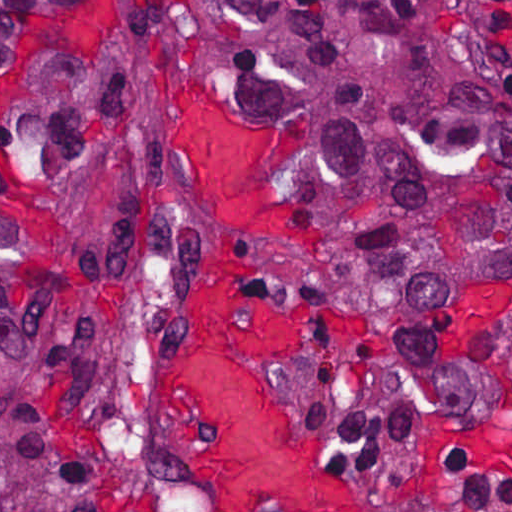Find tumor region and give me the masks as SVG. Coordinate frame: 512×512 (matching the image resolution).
I'll list each match as a JSON object with an SVG mask.
<instances>
[{
  "instance_id": "obj_1",
  "label": "tumor region",
  "mask_w": 512,
  "mask_h": 512,
  "mask_svg": "<svg viewBox=\"0 0 512 512\" xmlns=\"http://www.w3.org/2000/svg\"><path fill=\"white\" fill-rule=\"evenodd\" d=\"M314 123L347 256L275 286L383 307L355 460L471 415L454 304L512 291V44L490 0H0V512H115L52 357L178 206L151 156L181 78Z\"/></svg>"
}]
</instances>
